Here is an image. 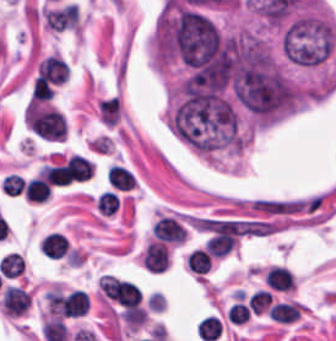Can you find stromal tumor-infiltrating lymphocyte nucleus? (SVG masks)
Listing matches in <instances>:
<instances>
[{"mask_svg": "<svg viewBox=\"0 0 336 341\" xmlns=\"http://www.w3.org/2000/svg\"><path fill=\"white\" fill-rule=\"evenodd\" d=\"M141 261L150 271H164L169 263L166 243L151 239L144 247Z\"/></svg>", "mask_w": 336, "mask_h": 341, "instance_id": "1", "label": "stromal tumor-infiltrating lymphocyte nucleus"}, {"mask_svg": "<svg viewBox=\"0 0 336 341\" xmlns=\"http://www.w3.org/2000/svg\"><path fill=\"white\" fill-rule=\"evenodd\" d=\"M68 70L65 60L59 55L52 53L45 55L42 63L37 69L36 76L49 82L61 83Z\"/></svg>", "mask_w": 336, "mask_h": 341, "instance_id": "2", "label": "stromal tumor-infiltrating lymphocyte nucleus"}, {"mask_svg": "<svg viewBox=\"0 0 336 341\" xmlns=\"http://www.w3.org/2000/svg\"><path fill=\"white\" fill-rule=\"evenodd\" d=\"M266 285L281 291H288L295 286L291 273L282 265L270 264L263 273Z\"/></svg>", "mask_w": 336, "mask_h": 341, "instance_id": "3", "label": "stromal tumor-infiltrating lymphocyte nucleus"}, {"mask_svg": "<svg viewBox=\"0 0 336 341\" xmlns=\"http://www.w3.org/2000/svg\"><path fill=\"white\" fill-rule=\"evenodd\" d=\"M68 239L61 233L49 232L39 241V250L47 258H58L67 254Z\"/></svg>", "mask_w": 336, "mask_h": 341, "instance_id": "4", "label": "stromal tumor-infiltrating lymphocyte nucleus"}, {"mask_svg": "<svg viewBox=\"0 0 336 341\" xmlns=\"http://www.w3.org/2000/svg\"><path fill=\"white\" fill-rule=\"evenodd\" d=\"M303 305L293 300L276 301L268 311L270 318L280 322H292L300 314Z\"/></svg>", "mask_w": 336, "mask_h": 341, "instance_id": "5", "label": "stromal tumor-infiltrating lymphocyte nucleus"}, {"mask_svg": "<svg viewBox=\"0 0 336 341\" xmlns=\"http://www.w3.org/2000/svg\"><path fill=\"white\" fill-rule=\"evenodd\" d=\"M22 193L26 200L42 202L50 194V185L43 176L37 174L27 179Z\"/></svg>", "mask_w": 336, "mask_h": 341, "instance_id": "6", "label": "stromal tumor-infiltrating lymphocyte nucleus"}, {"mask_svg": "<svg viewBox=\"0 0 336 341\" xmlns=\"http://www.w3.org/2000/svg\"><path fill=\"white\" fill-rule=\"evenodd\" d=\"M187 269L196 274H205L210 267L211 254L201 247H194L185 254Z\"/></svg>", "mask_w": 336, "mask_h": 341, "instance_id": "7", "label": "stromal tumor-infiltrating lymphocyte nucleus"}, {"mask_svg": "<svg viewBox=\"0 0 336 341\" xmlns=\"http://www.w3.org/2000/svg\"><path fill=\"white\" fill-rule=\"evenodd\" d=\"M41 332L45 341H65L67 335L64 321L56 317L45 319Z\"/></svg>", "mask_w": 336, "mask_h": 341, "instance_id": "8", "label": "stromal tumor-infiltrating lymphocyte nucleus"}, {"mask_svg": "<svg viewBox=\"0 0 336 341\" xmlns=\"http://www.w3.org/2000/svg\"><path fill=\"white\" fill-rule=\"evenodd\" d=\"M220 318L208 315L200 318L196 323V334L204 341H212L219 331Z\"/></svg>", "mask_w": 336, "mask_h": 341, "instance_id": "9", "label": "stromal tumor-infiltrating lymphocyte nucleus"}, {"mask_svg": "<svg viewBox=\"0 0 336 341\" xmlns=\"http://www.w3.org/2000/svg\"><path fill=\"white\" fill-rule=\"evenodd\" d=\"M118 207V198L114 192L102 190L97 196L96 209L103 215H113Z\"/></svg>", "mask_w": 336, "mask_h": 341, "instance_id": "10", "label": "stromal tumor-infiltrating lymphocyte nucleus"}, {"mask_svg": "<svg viewBox=\"0 0 336 341\" xmlns=\"http://www.w3.org/2000/svg\"><path fill=\"white\" fill-rule=\"evenodd\" d=\"M270 293L257 289L248 296V308L252 313H261L269 306Z\"/></svg>", "mask_w": 336, "mask_h": 341, "instance_id": "11", "label": "stromal tumor-infiltrating lymphocyte nucleus"}, {"mask_svg": "<svg viewBox=\"0 0 336 341\" xmlns=\"http://www.w3.org/2000/svg\"><path fill=\"white\" fill-rule=\"evenodd\" d=\"M24 180L21 174L16 172H9L2 178L0 189L6 195H16L22 190Z\"/></svg>", "mask_w": 336, "mask_h": 341, "instance_id": "12", "label": "stromal tumor-infiltrating lymphocyte nucleus"}, {"mask_svg": "<svg viewBox=\"0 0 336 341\" xmlns=\"http://www.w3.org/2000/svg\"><path fill=\"white\" fill-rule=\"evenodd\" d=\"M53 92L52 86L43 77L37 75L31 89L29 99L46 101L50 98Z\"/></svg>", "mask_w": 336, "mask_h": 341, "instance_id": "13", "label": "stromal tumor-infiltrating lymphocyte nucleus"}, {"mask_svg": "<svg viewBox=\"0 0 336 341\" xmlns=\"http://www.w3.org/2000/svg\"><path fill=\"white\" fill-rule=\"evenodd\" d=\"M231 322L244 323L250 315L249 308L242 301L231 303L227 313Z\"/></svg>", "mask_w": 336, "mask_h": 341, "instance_id": "14", "label": "stromal tumor-infiltrating lymphocyte nucleus"}]
</instances>
